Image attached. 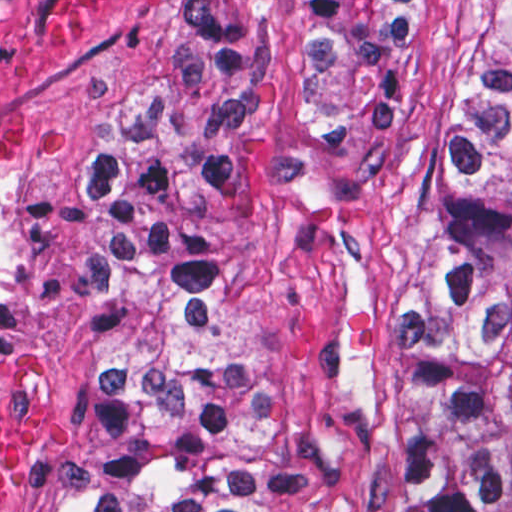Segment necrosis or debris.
Returning a JSON list of instances; mask_svg holds the SVG:
<instances>
[{
    "instance_id": "1",
    "label": "necrosis or debris",
    "mask_w": 512,
    "mask_h": 512,
    "mask_svg": "<svg viewBox=\"0 0 512 512\" xmlns=\"http://www.w3.org/2000/svg\"><path fill=\"white\" fill-rule=\"evenodd\" d=\"M24 348L0 343V512H28L52 424V400Z\"/></svg>"
}]
</instances>
